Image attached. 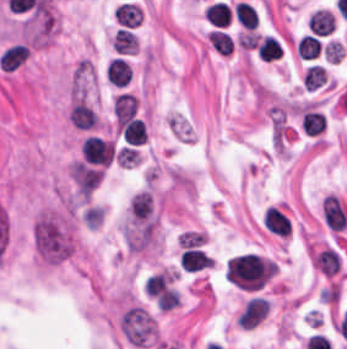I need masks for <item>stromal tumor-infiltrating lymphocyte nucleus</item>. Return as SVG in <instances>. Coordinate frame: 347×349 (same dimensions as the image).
<instances>
[{
	"instance_id": "bc302bb0",
	"label": "stromal tumor-infiltrating lymphocyte nucleus",
	"mask_w": 347,
	"mask_h": 349,
	"mask_svg": "<svg viewBox=\"0 0 347 349\" xmlns=\"http://www.w3.org/2000/svg\"><path fill=\"white\" fill-rule=\"evenodd\" d=\"M262 223L265 228L277 236H286L290 230V221L276 207H268L263 215Z\"/></svg>"
},
{
	"instance_id": "52c7bb5b",
	"label": "stromal tumor-infiltrating lymphocyte nucleus",
	"mask_w": 347,
	"mask_h": 349,
	"mask_svg": "<svg viewBox=\"0 0 347 349\" xmlns=\"http://www.w3.org/2000/svg\"><path fill=\"white\" fill-rule=\"evenodd\" d=\"M123 141L130 145H142L147 139V126L143 119L132 117L121 127Z\"/></svg>"
},
{
	"instance_id": "3290ff9b",
	"label": "stromal tumor-infiltrating lymphocyte nucleus",
	"mask_w": 347,
	"mask_h": 349,
	"mask_svg": "<svg viewBox=\"0 0 347 349\" xmlns=\"http://www.w3.org/2000/svg\"><path fill=\"white\" fill-rule=\"evenodd\" d=\"M114 114L120 123H127L136 114V95L124 91L116 94Z\"/></svg>"
},
{
	"instance_id": "abfb95fc",
	"label": "stromal tumor-infiltrating lymphocyte nucleus",
	"mask_w": 347,
	"mask_h": 349,
	"mask_svg": "<svg viewBox=\"0 0 347 349\" xmlns=\"http://www.w3.org/2000/svg\"><path fill=\"white\" fill-rule=\"evenodd\" d=\"M112 48L116 53H136L138 49L136 33L126 27H119L112 40Z\"/></svg>"
},
{
	"instance_id": "9ea309e8",
	"label": "stromal tumor-infiltrating lymphocyte nucleus",
	"mask_w": 347,
	"mask_h": 349,
	"mask_svg": "<svg viewBox=\"0 0 347 349\" xmlns=\"http://www.w3.org/2000/svg\"><path fill=\"white\" fill-rule=\"evenodd\" d=\"M69 119L76 126L91 128L96 123V113L81 101H74L71 106Z\"/></svg>"
},
{
	"instance_id": "f3e2335f",
	"label": "stromal tumor-infiltrating lymphocyte nucleus",
	"mask_w": 347,
	"mask_h": 349,
	"mask_svg": "<svg viewBox=\"0 0 347 349\" xmlns=\"http://www.w3.org/2000/svg\"><path fill=\"white\" fill-rule=\"evenodd\" d=\"M257 54L261 60L273 61L282 56V47L273 35H266L256 46Z\"/></svg>"
},
{
	"instance_id": "4f13568d",
	"label": "stromal tumor-infiltrating lymphocyte nucleus",
	"mask_w": 347,
	"mask_h": 349,
	"mask_svg": "<svg viewBox=\"0 0 347 349\" xmlns=\"http://www.w3.org/2000/svg\"><path fill=\"white\" fill-rule=\"evenodd\" d=\"M108 80L114 86H126L129 82L126 59L114 58L106 65Z\"/></svg>"
},
{
	"instance_id": "2a367800",
	"label": "stromal tumor-infiltrating lymphocyte nucleus",
	"mask_w": 347,
	"mask_h": 349,
	"mask_svg": "<svg viewBox=\"0 0 347 349\" xmlns=\"http://www.w3.org/2000/svg\"><path fill=\"white\" fill-rule=\"evenodd\" d=\"M208 34L213 48L220 54L233 52V38L228 32L214 28Z\"/></svg>"
},
{
	"instance_id": "4803ca6d",
	"label": "stromal tumor-infiltrating lymphocyte nucleus",
	"mask_w": 347,
	"mask_h": 349,
	"mask_svg": "<svg viewBox=\"0 0 347 349\" xmlns=\"http://www.w3.org/2000/svg\"><path fill=\"white\" fill-rule=\"evenodd\" d=\"M302 128L309 135H317L323 130V112L305 110L302 114Z\"/></svg>"
},
{
	"instance_id": "4245b91a",
	"label": "stromal tumor-infiltrating lymphocyte nucleus",
	"mask_w": 347,
	"mask_h": 349,
	"mask_svg": "<svg viewBox=\"0 0 347 349\" xmlns=\"http://www.w3.org/2000/svg\"><path fill=\"white\" fill-rule=\"evenodd\" d=\"M327 72L320 65H313L307 69L304 75V85L311 91L322 86Z\"/></svg>"
}]
</instances>
